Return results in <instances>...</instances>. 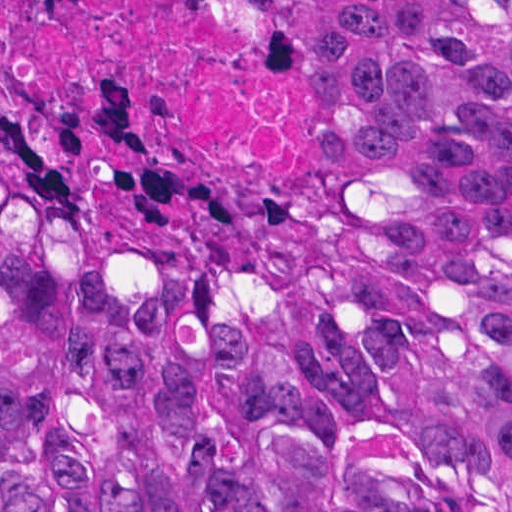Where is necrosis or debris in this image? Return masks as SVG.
Here are the masks:
<instances>
[{
    "label": "necrosis or debris",
    "instance_id": "obj_1",
    "mask_svg": "<svg viewBox=\"0 0 512 512\" xmlns=\"http://www.w3.org/2000/svg\"><path fill=\"white\" fill-rule=\"evenodd\" d=\"M0 169L115 215L300 208L333 175L315 0H0Z\"/></svg>",
    "mask_w": 512,
    "mask_h": 512
}]
</instances>
